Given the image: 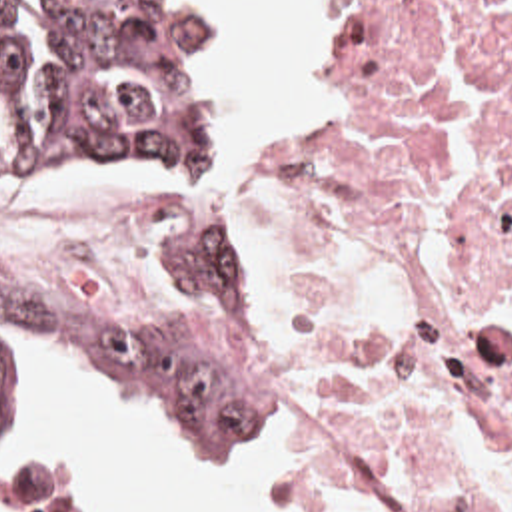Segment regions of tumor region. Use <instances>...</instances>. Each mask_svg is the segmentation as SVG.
I'll list each match as a JSON object with an SVG mask.
<instances>
[{
    "instance_id": "obj_1",
    "label": "tumor region",
    "mask_w": 512,
    "mask_h": 512,
    "mask_svg": "<svg viewBox=\"0 0 512 512\" xmlns=\"http://www.w3.org/2000/svg\"><path fill=\"white\" fill-rule=\"evenodd\" d=\"M16 0H0V15ZM210 101L178 0H48V79L0 43V171L192 167ZM56 348L120 398L166 418L248 428L254 279L202 221L150 303H56L0 281V346Z\"/></svg>"
}]
</instances>
